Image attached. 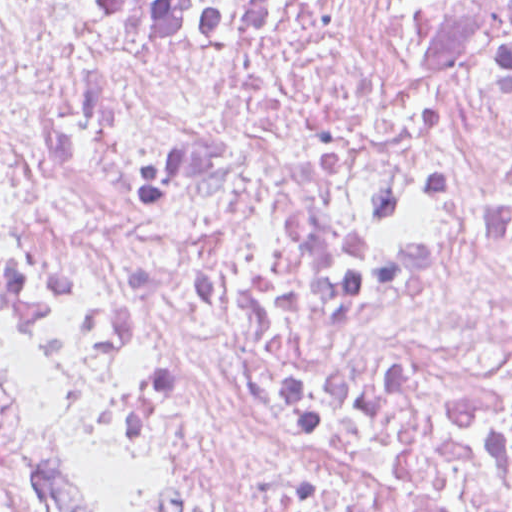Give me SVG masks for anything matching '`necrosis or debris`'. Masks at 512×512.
<instances>
[{"label": "necrosis or debris", "mask_w": 512, "mask_h": 512, "mask_svg": "<svg viewBox=\"0 0 512 512\" xmlns=\"http://www.w3.org/2000/svg\"><path fill=\"white\" fill-rule=\"evenodd\" d=\"M0 328L85 512H512V0H0Z\"/></svg>", "instance_id": "necrosis-or-debris-1"}]
</instances>
